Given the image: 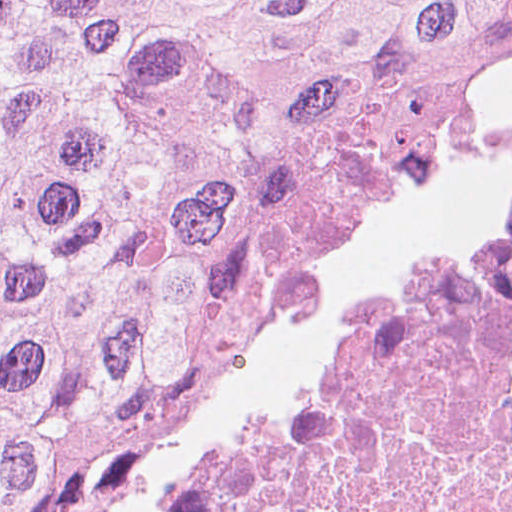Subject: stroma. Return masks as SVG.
I'll use <instances>...</instances> for the list:
<instances>
[{
  "label": "stroma",
  "mask_w": 512,
  "mask_h": 512,
  "mask_svg": "<svg viewBox=\"0 0 512 512\" xmlns=\"http://www.w3.org/2000/svg\"><path fill=\"white\" fill-rule=\"evenodd\" d=\"M512 178V124L402 181L343 234L258 265L185 322L159 364L49 465L17 512H151L214 430L333 339L396 260L483 217ZM1 512V0H0Z\"/></svg>",
  "instance_id": "obj_1"
}]
</instances>
